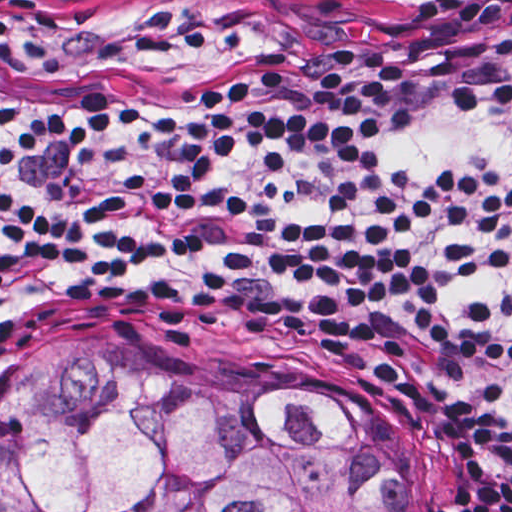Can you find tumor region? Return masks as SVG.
I'll return each mask as SVG.
<instances>
[{
	"label": "tumor region",
	"instance_id": "obj_1",
	"mask_svg": "<svg viewBox=\"0 0 512 512\" xmlns=\"http://www.w3.org/2000/svg\"><path fill=\"white\" fill-rule=\"evenodd\" d=\"M1 512H417L383 407L113 340L38 344L1 396Z\"/></svg>",
	"mask_w": 512,
	"mask_h": 512
}]
</instances>
